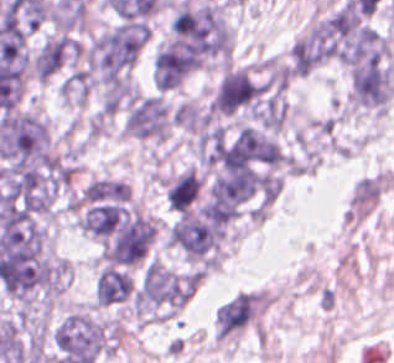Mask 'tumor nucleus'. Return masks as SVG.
<instances>
[{"mask_svg":"<svg viewBox=\"0 0 394 363\" xmlns=\"http://www.w3.org/2000/svg\"><path fill=\"white\" fill-rule=\"evenodd\" d=\"M171 116L177 126L192 132L197 128L201 120L199 109L192 103L184 101L175 106Z\"/></svg>","mask_w":394,"mask_h":363,"instance_id":"obj_7","label":"tumor nucleus"},{"mask_svg":"<svg viewBox=\"0 0 394 363\" xmlns=\"http://www.w3.org/2000/svg\"><path fill=\"white\" fill-rule=\"evenodd\" d=\"M201 177L191 167L180 172L166 187L165 197L172 209L185 213L198 200Z\"/></svg>","mask_w":394,"mask_h":363,"instance_id":"obj_6","label":"tumor nucleus"},{"mask_svg":"<svg viewBox=\"0 0 394 363\" xmlns=\"http://www.w3.org/2000/svg\"><path fill=\"white\" fill-rule=\"evenodd\" d=\"M123 130L135 138L163 139L168 132V114L161 95L132 100L124 114Z\"/></svg>","mask_w":394,"mask_h":363,"instance_id":"obj_4","label":"tumor nucleus"},{"mask_svg":"<svg viewBox=\"0 0 394 363\" xmlns=\"http://www.w3.org/2000/svg\"><path fill=\"white\" fill-rule=\"evenodd\" d=\"M166 45L197 60L227 57L229 28L218 4L176 1L169 12Z\"/></svg>","mask_w":394,"mask_h":363,"instance_id":"obj_1","label":"tumor nucleus"},{"mask_svg":"<svg viewBox=\"0 0 394 363\" xmlns=\"http://www.w3.org/2000/svg\"><path fill=\"white\" fill-rule=\"evenodd\" d=\"M393 83L394 75L384 53L351 67V98L355 106L384 111L393 91Z\"/></svg>","mask_w":394,"mask_h":363,"instance_id":"obj_3","label":"tumor nucleus"},{"mask_svg":"<svg viewBox=\"0 0 394 363\" xmlns=\"http://www.w3.org/2000/svg\"><path fill=\"white\" fill-rule=\"evenodd\" d=\"M129 194L126 184L121 179L104 175L85 186L77 194L73 206L80 214L125 201Z\"/></svg>","mask_w":394,"mask_h":363,"instance_id":"obj_5","label":"tumor nucleus"},{"mask_svg":"<svg viewBox=\"0 0 394 363\" xmlns=\"http://www.w3.org/2000/svg\"><path fill=\"white\" fill-rule=\"evenodd\" d=\"M265 85L246 69L231 66L222 72L209 99V112L216 116H250L264 97Z\"/></svg>","mask_w":394,"mask_h":363,"instance_id":"obj_2","label":"tumor nucleus"}]
</instances>
